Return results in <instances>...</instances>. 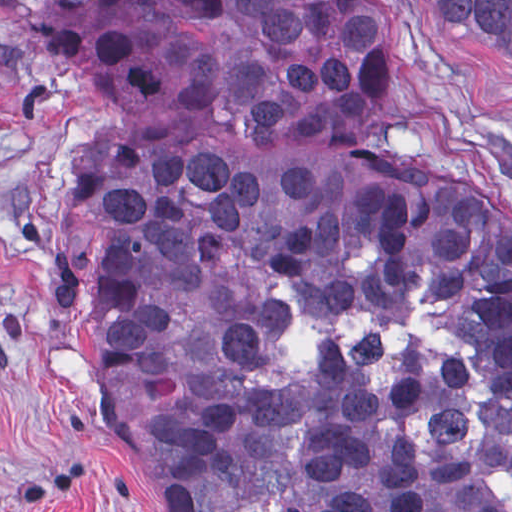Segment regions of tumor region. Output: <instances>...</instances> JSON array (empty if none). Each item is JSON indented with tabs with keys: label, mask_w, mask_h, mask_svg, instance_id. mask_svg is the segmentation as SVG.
Segmentation results:
<instances>
[{
	"label": "tumor region",
	"mask_w": 512,
	"mask_h": 512,
	"mask_svg": "<svg viewBox=\"0 0 512 512\" xmlns=\"http://www.w3.org/2000/svg\"><path fill=\"white\" fill-rule=\"evenodd\" d=\"M512 82V0H430ZM97 99L53 296L84 338L108 451L160 512H512V210L425 186L399 154L397 0H94L55 25ZM426 276L491 383L473 461H433L425 382L260 379L291 325L411 307Z\"/></svg>",
	"instance_id": "tumor-region-1"
}]
</instances>
